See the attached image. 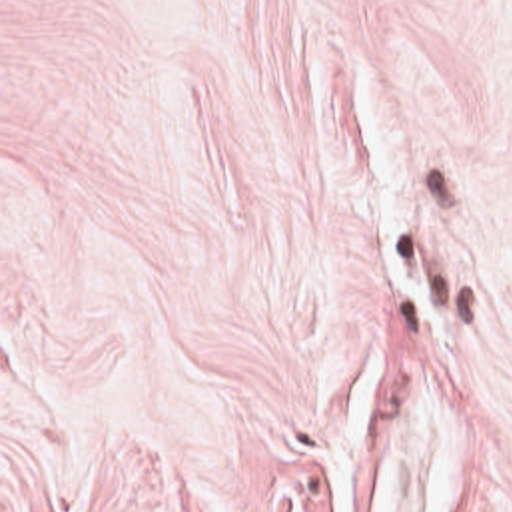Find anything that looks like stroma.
<instances>
[{
	"label": "stroma",
	"mask_w": 512,
	"mask_h": 512,
	"mask_svg": "<svg viewBox=\"0 0 512 512\" xmlns=\"http://www.w3.org/2000/svg\"><path fill=\"white\" fill-rule=\"evenodd\" d=\"M0 512H512V0H0Z\"/></svg>",
	"instance_id": "obj_1"
}]
</instances>
